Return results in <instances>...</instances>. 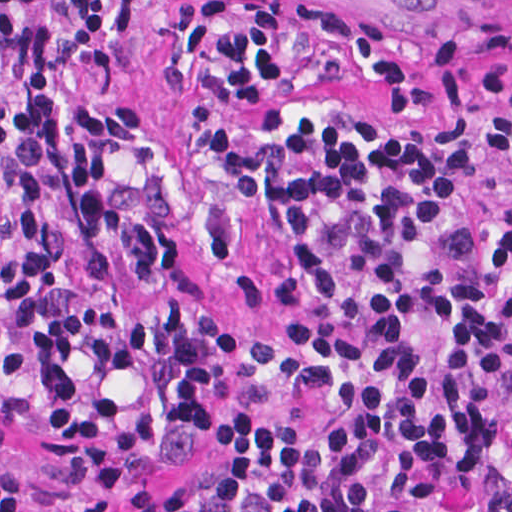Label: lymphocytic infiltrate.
<instances>
[{"mask_svg":"<svg viewBox=\"0 0 512 512\" xmlns=\"http://www.w3.org/2000/svg\"><path fill=\"white\" fill-rule=\"evenodd\" d=\"M512 2V0H510ZM145 0H114L104 43L81 53L95 77L118 73ZM104 0H0V58L17 107L0 89L2 182L20 217L11 327L53 403L56 449L92 473L139 475L152 436L129 411L77 391L73 358L104 374L136 355L113 304L80 292L61 256L56 187L67 192L87 284L104 276L107 240L158 281L172 262L167 227L113 196L103 149L137 139V105L84 109L63 83ZM468 40L441 29L398 55L386 25L351 6L308 0H187L162 81L187 89L202 68L195 123L231 110H274L313 65L337 78L356 67L385 112L416 119L438 105L468 110L493 95L492 155H512L508 33L479 63ZM212 158L240 196L271 209L296 241L283 289L286 343L249 347L260 384L285 399L327 397L333 420L288 431L225 417L207 440L234 485L261 487L269 512H512V307L473 272L453 286L420 280L409 250L417 227L453 196L455 158L396 136H347L321 118L273 140L214 131ZM13 446L0 420V512L28 510V477L1 472Z\"/></svg>","mask_w":512,"mask_h":512,"instance_id":"lymphocytic-infiltrate-1","label":"lymphocytic infiltrate"}]
</instances>
